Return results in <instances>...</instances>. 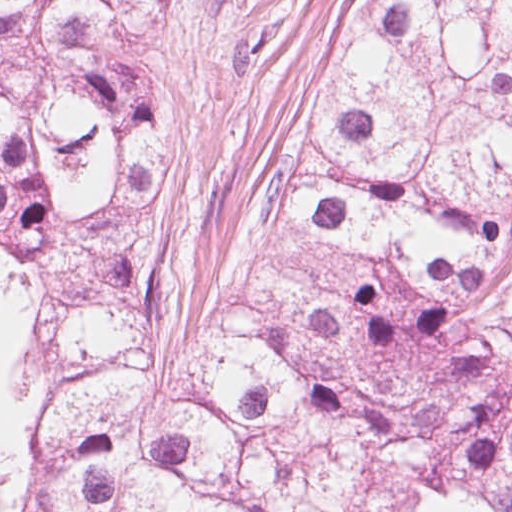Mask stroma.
I'll list each match as a JSON object with an SVG mask.
<instances>
[{"instance_id": "1", "label": "stroma", "mask_w": 512, "mask_h": 512, "mask_svg": "<svg viewBox=\"0 0 512 512\" xmlns=\"http://www.w3.org/2000/svg\"><path fill=\"white\" fill-rule=\"evenodd\" d=\"M17 492V445L0 440V512L9 510Z\"/></svg>"}]
</instances>
